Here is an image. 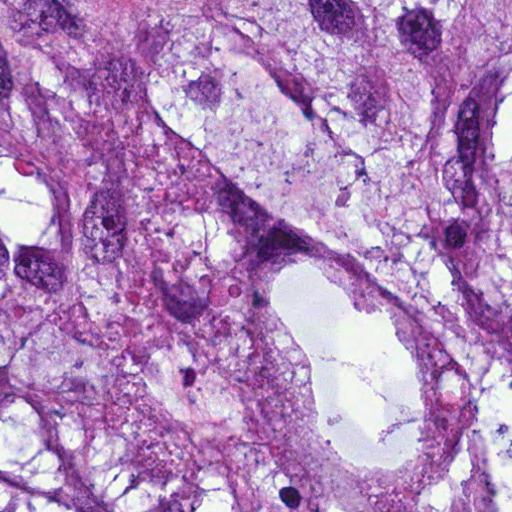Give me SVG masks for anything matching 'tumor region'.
<instances>
[{
	"label": "tumor region",
	"mask_w": 512,
	"mask_h": 512,
	"mask_svg": "<svg viewBox=\"0 0 512 512\" xmlns=\"http://www.w3.org/2000/svg\"><path fill=\"white\" fill-rule=\"evenodd\" d=\"M0 512H512V1H0Z\"/></svg>",
	"instance_id": "e687c5a6"
}]
</instances>
